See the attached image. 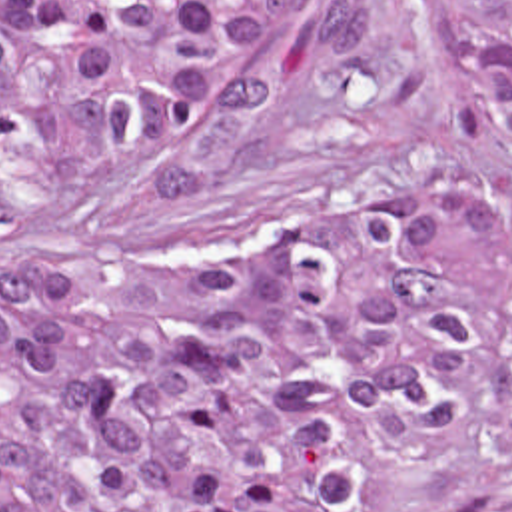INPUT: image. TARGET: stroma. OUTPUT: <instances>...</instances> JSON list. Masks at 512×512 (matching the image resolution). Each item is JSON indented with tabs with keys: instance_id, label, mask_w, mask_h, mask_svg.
Segmentation results:
<instances>
[{
	"instance_id": "35a3bbf8",
	"label": "stroma",
	"mask_w": 512,
	"mask_h": 512,
	"mask_svg": "<svg viewBox=\"0 0 512 512\" xmlns=\"http://www.w3.org/2000/svg\"><path fill=\"white\" fill-rule=\"evenodd\" d=\"M512 200V150L460 68L452 0H369V40L313 72L271 36L243 86L145 154L35 194L0 166V246L67 268H191L243 236L335 246L452 200ZM383 512H512V352L460 442L436 456L355 416Z\"/></svg>"
}]
</instances>
